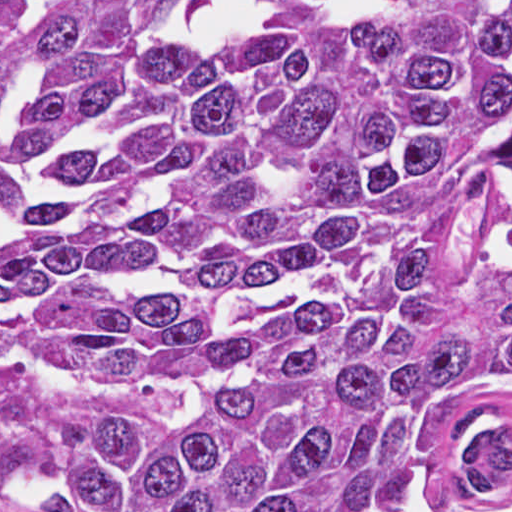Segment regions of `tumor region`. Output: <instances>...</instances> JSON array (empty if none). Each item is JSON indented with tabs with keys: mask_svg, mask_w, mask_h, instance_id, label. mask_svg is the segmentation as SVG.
<instances>
[{
	"mask_svg": "<svg viewBox=\"0 0 512 512\" xmlns=\"http://www.w3.org/2000/svg\"><path fill=\"white\" fill-rule=\"evenodd\" d=\"M0 512H512V0H0Z\"/></svg>",
	"mask_w": 512,
	"mask_h": 512,
	"instance_id": "1",
	"label": "tumor region"
}]
</instances>
